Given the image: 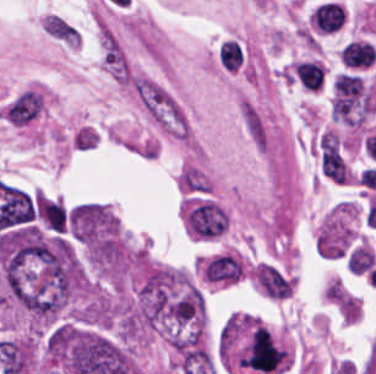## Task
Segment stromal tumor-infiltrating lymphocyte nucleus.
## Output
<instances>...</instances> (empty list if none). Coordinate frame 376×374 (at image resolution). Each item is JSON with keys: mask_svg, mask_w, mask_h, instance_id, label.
<instances>
[{"mask_svg": "<svg viewBox=\"0 0 376 374\" xmlns=\"http://www.w3.org/2000/svg\"><path fill=\"white\" fill-rule=\"evenodd\" d=\"M375 59L376 50H374L364 41L342 46L340 49L341 64L347 69H367L374 63Z\"/></svg>", "mask_w": 376, "mask_h": 374, "instance_id": "3", "label": "stromal tumor-infiltrating lymphocyte nucleus"}, {"mask_svg": "<svg viewBox=\"0 0 376 374\" xmlns=\"http://www.w3.org/2000/svg\"><path fill=\"white\" fill-rule=\"evenodd\" d=\"M186 225L199 239H212L227 230L228 216L221 206L199 198L185 209Z\"/></svg>", "mask_w": 376, "mask_h": 374, "instance_id": "1", "label": "stromal tumor-infiltrating lymphocyte nucleus"}, {"mask_svg": "<svg viewBox=\"0 0 376 374\" xmlns=\"http://www.w3.org/2000/svg\"><path fill=\"white\" fill-rule=\"evenodd\" d=\"M310 16L318 35H334L345 24L346 10L337 1H324L312 9Z\"/></svg>", "mask_w": 376, "mask_h": 374, "instance_id": "2", "label": "stromal tumor-infiltrating lymphocyte nucleus"}]
</instances>
